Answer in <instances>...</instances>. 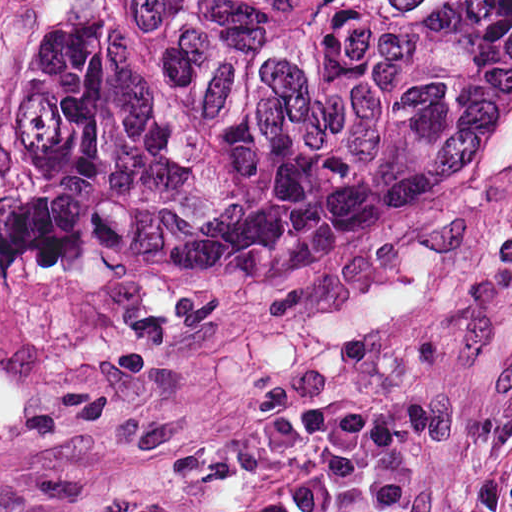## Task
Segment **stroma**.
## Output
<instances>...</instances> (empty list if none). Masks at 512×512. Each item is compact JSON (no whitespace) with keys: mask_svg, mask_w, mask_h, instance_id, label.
I'll list each match as a JSON object with an SVG mask.
<instances>
[{"mask_svg":"<svg viewBox=\"0 0 512 512\" xmlns=\"http://www.w3.org/2000/svg\"><path fill=\"white\" fill-rule=\"evenodd\" d=\"M57 3L0 0V125L23 29L46 36ZM511 365L512 147L343 262L218 276L189 254H98L58 281L0 263V483L133 472L334 391L423 429L411 512H442ZM290 462L245 463L172 512L248 506Z\"/></svg>","mask_w":512,"mask_h":512,"instance_id":"obj_1","label":"stroma"}]
</instances>
